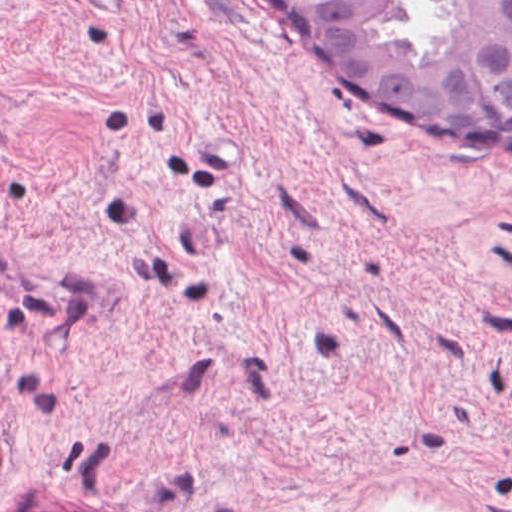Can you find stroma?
Instances as JSON below:
<instances>
[{
  "label": "stroma",
  "mask_w": 512,
  "mask_h": 512,
  "mask_svg": "<svg viewBox=\"0 0 512 512\" xmlns=\"http://www.w3.org/2000/svg\"><path fill=\"white\" fill-rule=\"evenodd\" d=\"M512 512V153L347 97L270 0H0V512Z\"/></svg>",
  "instance_id": "1"
}]
</instances>
